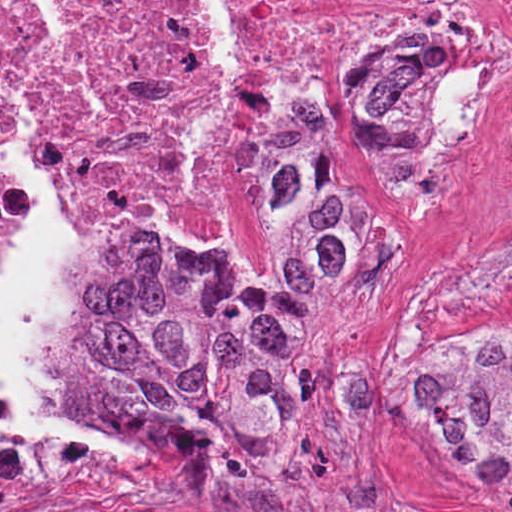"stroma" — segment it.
Returning <instances> with one entry per match:
<instances>
[{"label":"stroma","mask_w":512,"mask_h":512,"mask_svg":"<svg viewBox=\"0 0 512 512\" xmlns=\"http://www.w3.org/2000/svg\"><path fill=\"white\" fill-rule=\"evenodd\" d=\"M325 69L337 109L356 72L326 36ZM351 156L383 260L315 307L283 427L221 466L133 433L112 410L108 381L83 362L78 336L115 244L105 219L44 179L78 229L65 390L110 424L117 435L94 444L125 468L0 488V512H512V473H480L405 422L407 391L429 361L484 332L500 346L512 341V296L478 284L512 256V128L425 195L394 199L370 160Z\"/></svg>","instance_id":"stroma-1"}]
</instances>
